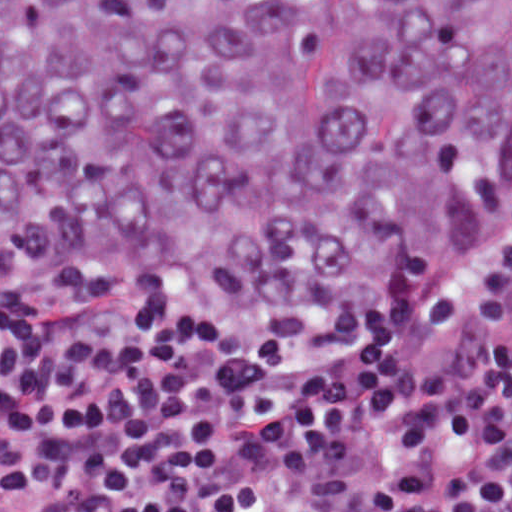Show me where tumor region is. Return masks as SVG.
Listing matches in <instances>:
<instances>
[{"label":"tumor region","instance_id":"obj_1","mask_svg":"<svg viewBox=\"0 0 512 512\" xmlns=\"http://www.w3.org/2000/svg\"><path fill=\"white\" fill-rule=\"evenodd\" d=\"M512 208V0H0V294L367 362Z\"/></svg>","mask_w":512,"mask_h":512}]
</instances>
